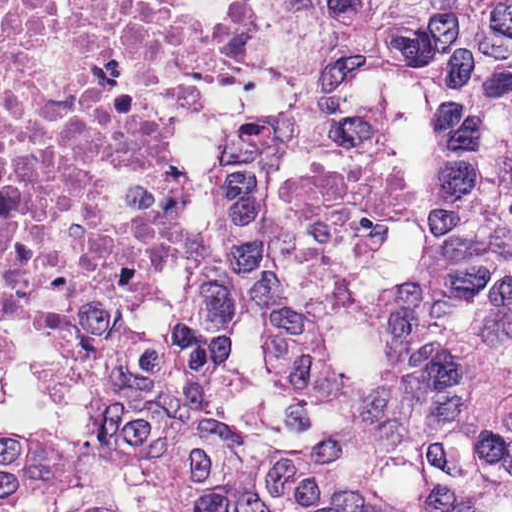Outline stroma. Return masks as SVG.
<instances>
[{"label": "stroma", "mask_w": 512, "mask_h": 512, "mask_svg": "<svg viewBox=\"0 0 512 512\" xmlns=\"http://www.w3.org/2000/svg\"><path fill=\"white\" fill-rule=\"evenodd\" d=\"M454 1L260 0L263 67L247 82L161 97L168 136L188 148L389 58L397 13Z\"/></svg>", "instance_id": "1"}]
</instances>
